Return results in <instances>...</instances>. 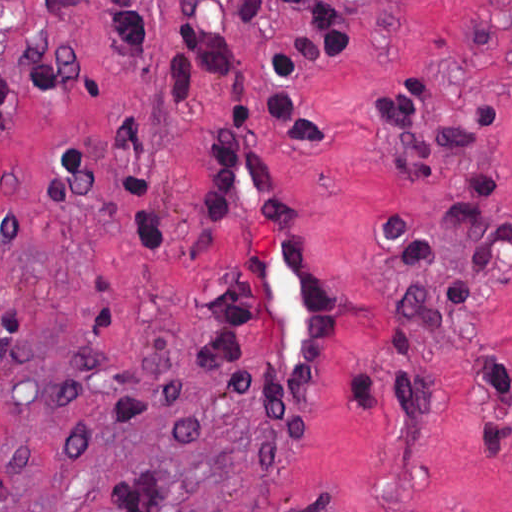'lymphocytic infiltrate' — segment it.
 <instances>
[{"mask_svg":"<svg viewBox=\"0 0 512 512\" xmlns=\"http://www.w3.org/2000/svg\"><path fill=\"white\" fill-rule=\"evenodd\" d=\"M290 10L297 18V32L268 55L266 125L279 128L288 149L299 160L331 163L335 154L332 135L329 130L318 128L305 119L296 103V90L300 80L315 68L358 48V25L345 0H293ZM418 95H406L388 105L385 126L398 135L419 131L422 116L415 103ZM476 111L475 130L445 128L437 133L439 139L446 144H469L489 131H499L496 106L483 103ZM256 148L262 173L274 192L277 210L288 222L265 168L261 145H254L252 141V108L241 103L236 115L206 148L199 167L196 242L210 255L222 235L241 221V243L227 274L214 286L197 314L195 343L208 371L227 395L267 421L282 438L295 437L303 441L297 436L311 424L329 375L331 284L327 271L314 258L323 273L328 300L326 363L316 394L295 402L282 397L266 363L262 263L234 194V172L240 156ZM398 166L421 185L436 168V153L428 143L421 144L417 146L415 168ZM500 182H505L504 176L471 178L466 185L475 194L488 195ZM440 215L467 262L488 279L495 266L512 256V220L494 219L471 200H453ZM371 226L398 266L400 276L449 272L455 299L469 298V274L461 265L442 255L419 222L407 216H388L371 219ZM299 244L306 250L301 242ZM399 314L429 330H439L443 326V299L411 292L401 285L391 317ZM381 353L414 357L416 338L390 318ZM490 362L493 389L498 399L512 405V368L494 358H490ZM382 370L394 408L402 415H415L424 409L425 390L416 380L397 378L384 367ZM483 443L494 450L478 447L488 458L512 453V422L488 420ZM114 512H178V484L166 468L128 481L114 500Z\"/></svg>","mask_w":512,"mask_h":512,"instance_id":"f902f5d3","label":"lymphocytic infiltrate"}]
</instances>
